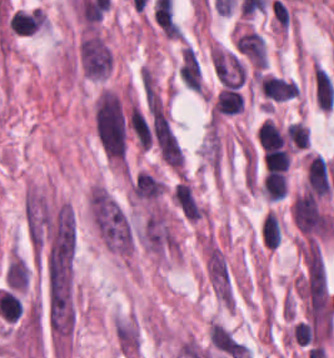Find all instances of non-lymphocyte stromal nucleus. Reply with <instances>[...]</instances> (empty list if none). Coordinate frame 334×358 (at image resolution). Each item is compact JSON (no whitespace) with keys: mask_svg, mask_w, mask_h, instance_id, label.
I'll list each match as a JSON object with an SVG mask.
<instances>
[{"mask_svg":"<svg viewBox=\"0 0 334 358\" xmlns=\"http://www.w3.org/2000/svg\"><path fill=\"white\" fill-rule=\"evenodd\" d=\"M292 219L301 232L319 238L333 233V218L309 192L297 194L292 206Z\"/></svg>","mask_w":334,"mask_h":358,"instance_id":"obj_4","label":"non-lymphocyte stromal nucleus"},{"mask_svg":"<svg viewBox=\"0 0 334 358\" xmlns=\"http://www.w3.org/2000/svg\"><path fill=\"white\" fill-rule=\"evenodd\" d=\"M172 200L183 216L191 220H199L204 206L187 177H179L171 191Z\"/></svg>","mask_w":334,"mask_h":358,"instance_id":"obj_9","label":"non-lymphocyte stromal nucleus"},{"mask_svg":"<svg viewBox=\"0 0 334 358\" xmlns=\"http://www.w3.org/2000/svg\"><path fill=\"white\" fill-rule=\"evenodd\" d=\"M306 179L310 193L321 197L330 193L331 180L322 156L307 153Z\"/></svg>","mask_w":334,"mask_h":358,"instance_id":"obj_12","label":"non-lymphocyte stromal nucleus"},{"mask_svg":"<svg viewBox=\"0 0 334 358\" xmlns=\"http://www.w3.org/2000/svg\"><path fill=\"white\" fill-rule=\"evenodd\" d=\"M163 191L161 180L145 171H138L129 186V193L137 202L155 203Z\"/></svg>","mask_w":334,"mask_h":358,"instance_id":"obj_11","label":"non-lymphocyte stromal nucleus"},{"mask_svg":"<svg viewBox=\"0 0 334 358\" xmlns=\"http://www.w3.org/2000/svg\"><path fill=\"white\" fill-rule=\"evenodd\" d=\"M131 116V105L109 89L103 88L92 104L94 134L103 153L113 162L123 161Z\"/></svg>","mask_w":334,"mask_h":358,"instance_id":"obj_1","label":"non-lymphocyte stromal nucleus"},{"mask_svg":"<svg viewBox=\"0 0 334 358\" xmlns=\"http://www.w3.org/2000/svg\"><path fill=\"white\" fill-rule=\"evenodd\" d=\"M114 343L124 358H138L142 330L133 313H119L112 321Z\"/></svg>","mask_w":334,"mask_h":358,"instance_id":"obj_7","label":"non-lymphocyte stromal nucleus"},{"mask_svg":"<svg viewBox=\"0 0 334 358\" xmlns=\"http://www.w3.org/2000/svg\"><path fill=\"white\" fill-rule=\"evenodd\" d=\"M136 238L141 247L154 255H164L178 247L177 239L162 209L152 208L143 218Z\"/></svg>","mask_w":334,"mask_h":358,"instance_id":"obj_3","label":"non-lymphocyte stromal nucleus"},{"mask_svg":"<svg viewBox=\"0 0 334 358\" xmlns=\"http://www.w3.org/2000/svg\"><path fill=\"white\" fill-rule=\"evenodd\" d=\"M29 269L23 258L13 254L5 271V280L9 287L26 288Z\"/></svg>","mask_w":334,"mask_h":358,"instance_id":"obj_15","label":"non-lymphocyte stromal nucleus"},{"mask_svg":"<svg viewBox=\"0 0 334 358\" xmlns=\"http://www.w3.org/2000/svg\"><path fill=\"white\" fill-rule=\"evenodd\" d=\"M207 268L218 294L227 306L232 307V285L227 264L222 254L211 246L208 249Z\"/></svg>","mask_w":334,"mask_h":358,"instance_id":"obj_10","label":"non-lymphocyte stromal nucleus"},{"mask_svg":"<svg viewBox=\"0 0 334 358\" xmlns=\"http://www.w3.org/2000/svg\"><path fill=\"white\" fill-rule=\"evenodd\" d=\"M236 49L253 65L265 67L267 65L264 39L254 30L242 33L235 42Z\"/></svg>","mask_w":334,"mask_h":358,"instance_id":"obj_13","label":"non-lymphocyte stromal nucleus"},{"mask_svg":"<svg viewBox=\"0 0 334 358\" xmlns=\"http://www.w3.org/2000/svg\"><path fill=\"white\" fill-rule=\"evenodd\" d=\"M89 206L93 226L106 246L128 254L134 245V231L125 210L97 186L89 194Z\"/></svg>","mask_w":334,"mask_h":358,"instance_id":"obj_2","label":"non-lymphocyte stromal nucleus"},{"mask_svg":"<svg viewBox=\"0 0 334 358\" xmlns=\"http://www.w3.org/2000/svg\"><path fill=\"white\" fill-rule=\"evenodd\" d=\"M91 79L104 58L109 46L92 28L83 34Z\"/></svg>","mask_w":334,"mask_h":358,"instance_id":"obj_14","label":"non-lymphocyte stromal nucleus"},{"mask_svg":"<svg viewBox=\"0 0 334 358\" xmlns=\"http://www.w3.org/2000/svg\"><path fill=\"white\" fill-rule=\"evenodd\" d=\"M211 66L221 85L244 88L248 80L246 60L235 50L215 48L210 54Z\"/></svg>","mask_w":334,"mask_h":358,"instance_id":"obj_5","label":"non-lymphocyte stromal nucleus"},{"mask_svg":"<svg viewBox=\"0 0 334 358\" xmlns=\"http://www.w3.org/2000/svg\"><path fill=\"white\" fill-rule=\"evenodd\" d=\"M153 140L160 157L172 168L180 169L183 164L181 148L168 119H154Z\"/></svg>","mask_w":334,"mask_h":358,"instance_id":"obj_8","label":"non-lymphocyte stromal nucleus"},{"mask_svg":"<svg viewBox=\"0 0 334 358\" xmlns=\"http://www.w3.org/2000/svg\"><path fill=\"white\" fill-rule=\"evenodd\" d=\"M24 220L32 244L40 248L49 231L50 209L35 189L29 188L25 195Z\"/></svg>","mask_w":334,"mask_h":358,"instance_id":"obj_6","label":"non-lymphocyte stromal nucleus"}]
</instances>
